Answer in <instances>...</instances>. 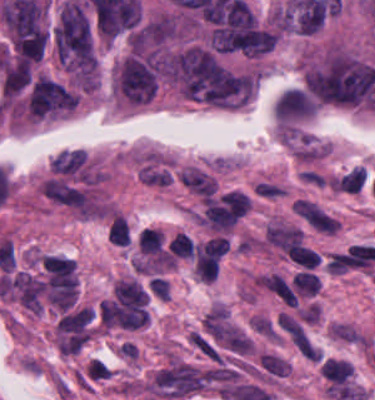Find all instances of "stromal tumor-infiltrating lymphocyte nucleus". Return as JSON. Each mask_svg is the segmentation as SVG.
<instances>
[{
    "mask_svg": "<svg viewBox=\"0 0 375 400\" xmlns=\"http://www.w3.org/2000/svg\"><path fill=\"white\" fill-rule=\"evenodd\" d=\"M292 282L300 294L314 297L320 285L317 274L305 271L297 272Z\"/></svg>",
    "mask_w": 375,
    "mask_h": 400,
    "instance_id": "obj_3",
    "label": "stromal tumor-infiltrating lymphocyte nucleus"
},
{
    "mask_svg": "<svg viewBox=\"0 0 375 400\" xmlns=\"http://www.w3.org/2000/svg\"><path fill=\"white\" fill-rule=\"evenodd\" d=\"M107 239L116 245H126L129 240V227L123 214L115 213L110 222Z\"/></svg>",
    "mask_w": 375,
    "mask_h": 400,
    "instance_id": "obj_2",
    "label": "stromal tumor-infiltrating lymphocyte nucleus"
},
{
    "mask_svg": "<svg viewBox=\"0 0 375 400\" xmlns=\"http://www.w3.org/2000/svg\"><path fill=\"white\" fill-rule=\"evenodd\" d=\"M287 255L291 262L310 270L321 263L320 254L303 244L296 243Z\"/></svg>",
    "mask_w": 375,
    "mask_h": 400,
    "instance_id": "obj_1",
    "label": "stromal tumor-infiltrating lymphocyte nucleus"
},
{
    "mask_svg": "<svg viewBox=\"0 0 375 400\" xmlns=\"http://www.w3.org/2000/svg\"><path fill=\"white\" fill-rule=\"evenodd\" d=\"M177 254L183 257L193 256V240L184 233H177L176 236Z\"/></svg>",
    "mask_w": 375,
    "mask_h": 400,
    "instance_id": "obj_4",
    "label": "stromal tumor-infiltrating lymphocyte nucleus"
},
{
    "mask_svg": "<svg viewBox=\"0 0 375 400\" xmlns=\"http://www.w3.org/2000/svg\"><path fill=\"white\" fill-rule=\"evenodd\" d=\"M250 92H251V78L247 74L241 104L248 99Z\"/></svg>",
    "mask_w": 375,
    "mask_h": 400,
    "instance_id": "obj_5",
    "label": "stromal tumor-infiltrating lymphocyte nucleus"
}]
</instances>
